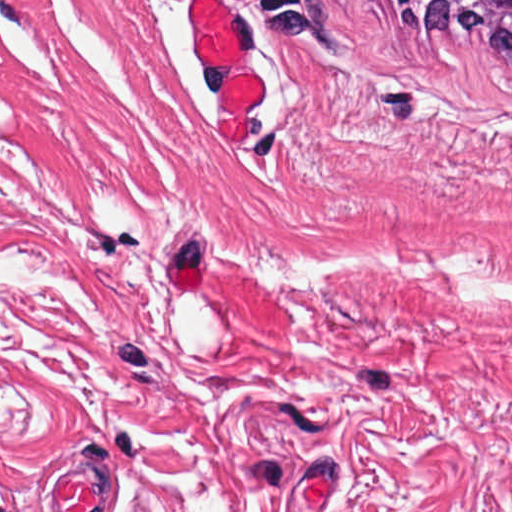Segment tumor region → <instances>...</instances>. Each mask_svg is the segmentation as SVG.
Instances as JSON below:
<instances>
[{"mask_svg": "<svg viewBox=\"0 0 512 512\" xmlns=\"http://www.w3.org/2000/svg\"><path fill=\"white\" fill-rule=\"evenodd\" d=\"M433 48L481 46L512 59V0H373Z\"/></svg>", "mask_w": 512, "mask_h": 512, "instance_id": "obj_1", "label": "tumor region"}]
</instances>
